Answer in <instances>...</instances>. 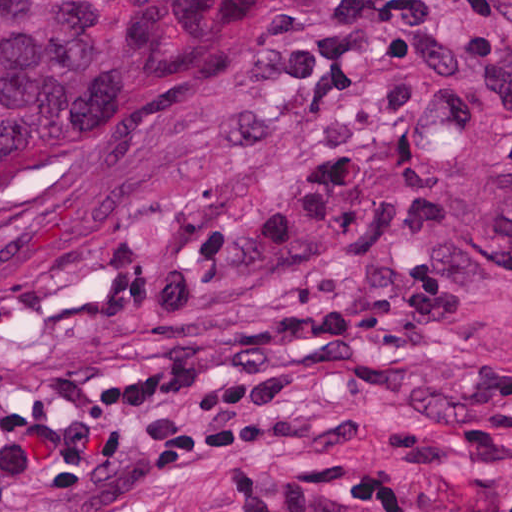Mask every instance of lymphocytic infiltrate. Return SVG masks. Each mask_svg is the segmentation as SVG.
I'll use <instances>...</instances> for the list:
<instances>
[{
  "label": "lymphocytic infiltrate",
  "mask_w": 512,
  "mask_h": 512,
  "mask_svg": "<svg viewBox=\"0 0 512 512\" xmlns=\"http://www.w3.org/2000/svg\"><path fill=\"white\" fill-rule=\"evenodd\" d=\"M220 480L239 512H442L423 489L403 486L354 456L320 460L293 481H273L258 470Z\"/></svg>",
  "instance_id": "obj_1"
}]
</instances>
